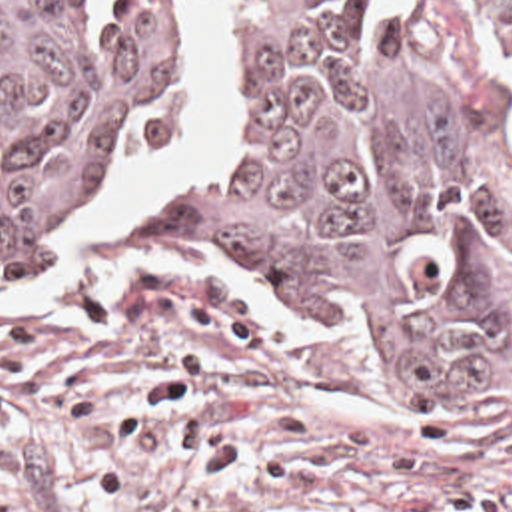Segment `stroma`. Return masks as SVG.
<instances>
[{
  "label": "stroma",
  "instance_id": "obj_1",
  "mask_svg": "<svg viewBox=\"0 0 512 512\" xmlns=\"http://www.w3.org/2000/svg\"><path fill=\"white\" fill-rule=\"evenodd\" d=\"M195 1L171 17L167 119L91 203L177 133ZM215 3L219 105L175 191L221 141L233 0ZM371 35L485 233V387L409 399L333 313L175 255L173 193L129 237L81 221L0 287V512H512V69L467 55L463 0H371Z\"/></svg>",
  "mask_w": 512,
  "mask_h": 512
}]
</instances>
